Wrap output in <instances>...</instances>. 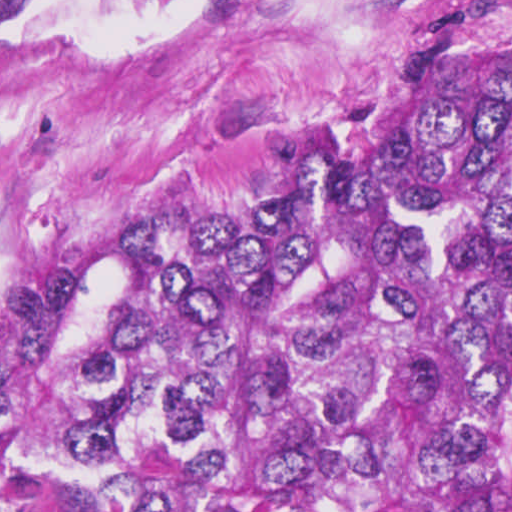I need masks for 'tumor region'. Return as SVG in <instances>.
<instances>
[{
    "instance_id": "1",
    "label": "tumor region",
    "mask_w": 512,
    "mask_h": 512,
    "mask_svg": "<svg viewBox=\"0 0 512 512\" xmlns=\"http://www.w3.org/2000/svg\"><path fill=\"white\" fill-rule=\"evenodd\" d=\"M0 512H512V60L35 282L0 316Z\"/></svg>"
}]
</instances>
